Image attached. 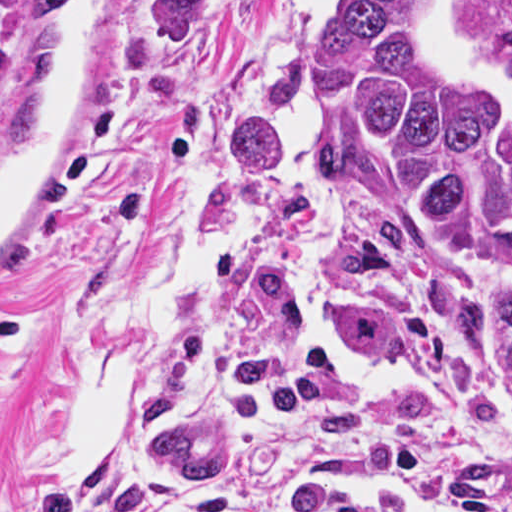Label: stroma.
<instances>
[{"label":"stroma","instance_id":"stroma-1","mask_svg":"<svg viewBox=\"0 0 512 512\" xmlns=\"http://www.w3.org/2000/svg\"><path fill=\"white\" fill-rule=\"evenodd\" d=\"M289 0H236L216 42L190 65L153 57L163 0H124L87 103L69 132V178L14 233L0 272V512L52 493L110 510L161 497L186 512L219 489L299 483L374 497L409 512H458L375 460L292 416L314 460L272 477L156 486L129 476L81 482L61 386L93 292L135 259L171 191L202 163L201 131L226 99L234 64ZM71 0H0V133L59 42ZM442 30L470 60L512 34V0H436ZM313 181L289 197L278 229L222 281L218 366L270 355L297 390L462 470L512 512V343L469 318L455 296L452 241L425 226L408 245L411 338L403 357H362L329 337L340 175L319 110Z\"/></svg>","mask_w":512,"mask_h":512}]
</instances>
